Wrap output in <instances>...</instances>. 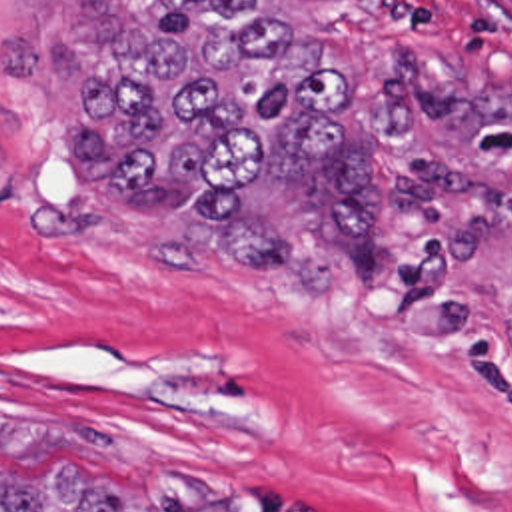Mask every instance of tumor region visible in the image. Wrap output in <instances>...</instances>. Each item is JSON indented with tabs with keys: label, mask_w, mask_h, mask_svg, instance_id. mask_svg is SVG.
<instances>
[{
	"label": "tumor region",
	"mask_w": 512,
	"mask_h": 512,
	"mask_svg": "<svg viewBox=\"0 0 512 512\" xmlns=\"http://www.w3.org/2000/svg\"><path fill=\"white\" fill-rule=\"evenodd\" d=\"M72 162L102 194L166 208L210 260L308 296L392 302L414 252L464 260L490 234L474 142L512 84L452 88L410 56L314 30L346 0H94ZM0 445L96 433L0 419ZM0 512H140L76 465L0 477Z\"/></svg>",
	"instance_id": "tumor-region-1"
}]
</instances>
